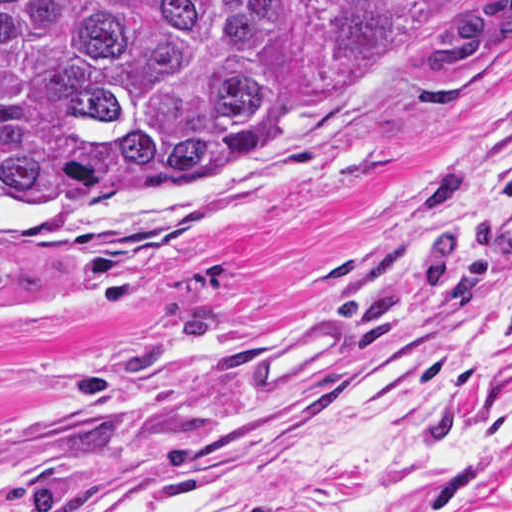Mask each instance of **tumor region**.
Here are the masks:
<instances>
[{
  "label": "tumor region",
  "instance_id": "tumor-region-1",
  "mask_svg": "<svg viewBox=\"0 0 512 512\" xmlns=\"http://www.w3.org/2000/svg\"><path fill=\"white\" fill-rule=\"evenodd\" d=\"M326 40L387 76L512 54V0H315ZM293 0H0V204L161 188L284 116ZM23 276L0 261V303Z\"/></svg>",
  "mask_w": 512,
  "mask_h": 512
}]
</instances>
